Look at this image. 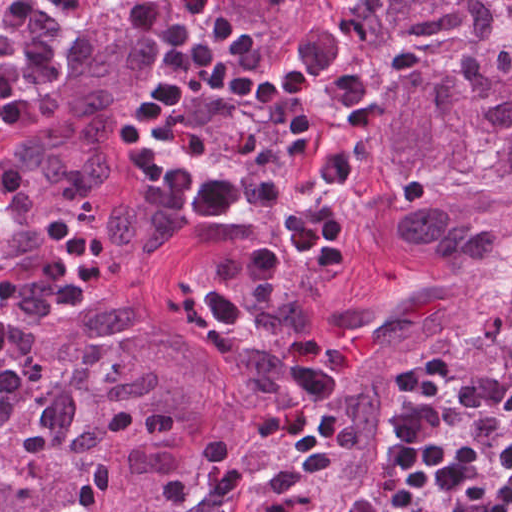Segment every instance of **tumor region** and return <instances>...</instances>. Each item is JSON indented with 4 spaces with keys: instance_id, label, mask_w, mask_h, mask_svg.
I'll list each match as a JSON object with an SVG mask.
<instances>
[{
    "instance_id": "obj_1",
    "label": "tumor region",
    "mask_w": 512,
    "mask_h": 512,
    "mask_svg": "<svg viewBox=\"0 0 512 512\" xmlns=\"http://www.w3.org/2000/svg\"><path fill=\"white\" fill-rule=\"evenodd\" d=\"M371 1L404 37L392 71L512 178V0Z\"/></svg>"
}]
</instances>
